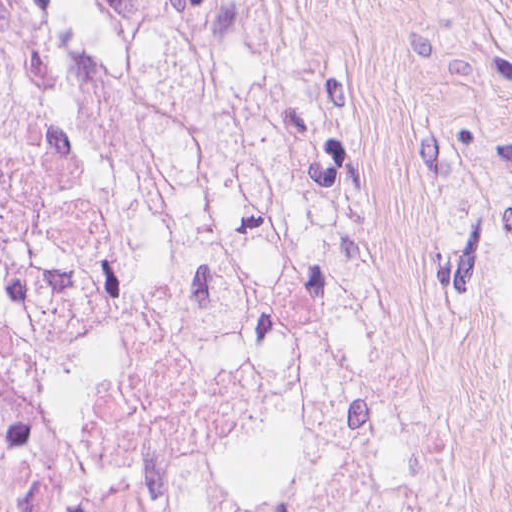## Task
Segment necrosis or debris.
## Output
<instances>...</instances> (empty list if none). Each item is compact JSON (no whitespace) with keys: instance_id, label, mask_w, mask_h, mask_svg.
Instances as JSON below:
<instances>
[{"instance_id":"4bbe7bcc","label":"necrosis or debris","mask_w":512,"mask_h":512,"mask_svg":"<svg viewBox=\"0 0 512 512\" xmlns=\"http://www.w3.org/2000/svg\"><path fill=\"white\" fill-rule=\"evenodd\" d=\"M324 169L305 0H0V512H399Z\"/></svg>"}]
</instances>
